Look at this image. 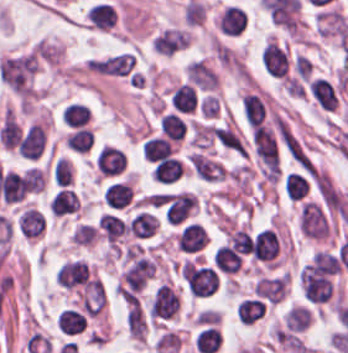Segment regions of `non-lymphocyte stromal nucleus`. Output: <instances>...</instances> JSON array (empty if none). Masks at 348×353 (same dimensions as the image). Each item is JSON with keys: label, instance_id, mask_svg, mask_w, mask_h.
Here are the masks:
<instances>
[{"label": "non-lymphocyte stromal nucleus", "instance_id": "obj_1", "mask_svg": "<svg viewBox=\"0 0 348 353\" xmlns=\"http://www.w3.org/2000/svg\"><path fill=\"white\" fill-rule=\"evenodd\" d=\"M186 161L194 174L206 181H220L225 173L223 164L204 151H191Z\"/></svg>", "mask_w": 348, "mask_h": 353}, {"label": "non-lymphocyte stromal nucleus", "instance_id": "obj_2", "mask_svg": "<svg viewBox=\"0 0 348 353\" xmlns=\"http://www.w3.org/2000/svg\"><path fill=\"white\" fill-rule=\"evenodd\" d=\"M317 29L325 36L341 39L348 31V19L342 11L324 7L317 15Z\"/></svg>", "mask_w": 348, "mask_h": 353}]
</instances>
